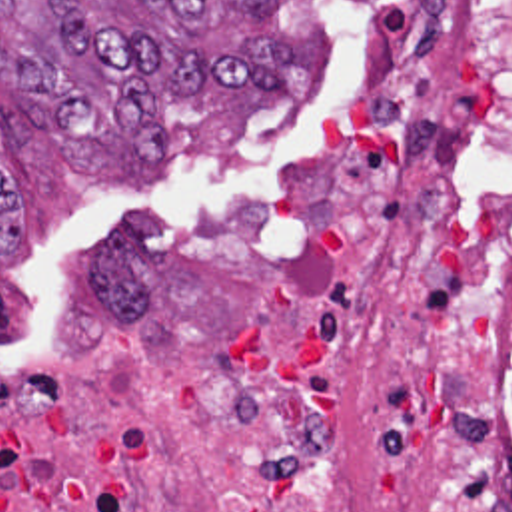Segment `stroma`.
<instances>
[{"mask_svg": "<svg viewBox=\"0 0 512 512\" xmlns=\"http://www.w3.org/2000/svg\"><path fill=\"white\" fill-rule=\"evenodd\" d=\"M385 0H279L269 18H211L217 38L291 40L279 96L205 90L163 110V156L139 164L105 148L63 154L49 114L0 80V170L21 204V240L0 252V371L57 314L97 254L131 222L223 214L265 196L327 138L341 68Z\"/></svg>", "mask_w": 512, "mask_h": 512, "instance_id": "1", "label": "stroma"}]
</instances>
